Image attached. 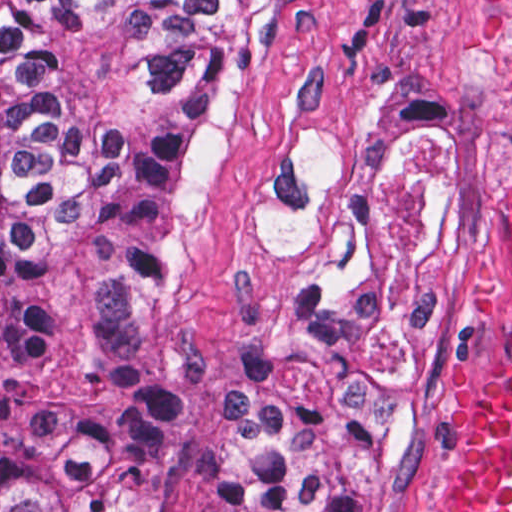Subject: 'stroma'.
I'll return each mask as SVG.
<instances>
[{"mask_svg": "<svg viewBox=\"0 0 512 512\" xmlns=\"http://www.w3.org/2000/svg\"><path fill=\"white\" fill-rule=\"evenodd\" d=\"M512 0H277L215 120L157 265V341L192 368L235 357L300 286L372 172L439 143L451 278L439 386L390 512H435L475 389V319L512 203L500 60ZM21 204L0 117V230ZM223 452L168 448L141 512H219Z\"/></svg>", "mask_w": 512, "mask_h": 512, "instance_id": "1", "label": "stroma"}]
</instances>
